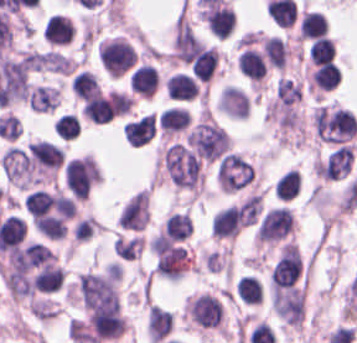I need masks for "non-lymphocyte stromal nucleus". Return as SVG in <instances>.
Instances as JSON below:
<instances>
[{"mask_svg": "<svg viewBox=\"0 0 357 343\" xmlns=\"http://www.w3.org/2000/svg\"><path fill=\"white\" fill-rule=\"evenodd\" d=\"M168 177L179 187L197 189L201 184L199 157L184 143L172 142L161 155Z\"/></svg>", "mask_w": 357, "mask_h": 343, "instance_id": "obj_1", "label": "non-lymphocyte stromal nucleus"}, {"mask_svg": "<svg viewBox=\"0 0 357 343\" xmlns=\"http://www.w3.org/2000/svg\"><path fill=\"white\" fill-rule=\"evenodd\" d=\"M313 129L318 139L343 145L357 133L354 114L339 107L320 106L312 115Z\"/></svg>", "mask_w": 357, "mask_h": 343, "instance_id": "obj_2", "label": "non-lymphocyte stromal nucleus"}, {"mask_svg": "<svg viewBox=\"0 0 357 343\" xmlns=\"http://www.w3.org/2000/svg\"><path fill=\"white\" fill-rule=\"evenodd\" d=\"M214 178L220 191L235 194L255 184L256 171L241 154L229 151L216 164Z\"/></svg>", "mask_w": 357, "mask_h": 343, "instance_id": "obj_3", "label": "non-lymphocyte stromal nucleus"}, {"mask_svg": "<svg viewBox=\"0 0 357 343\" xmlns=\"http://www.w3.org/2000/svg\"><path fill=\"white\" fill-rule=\"evenodd\" d=\"M186 142L199 158L210 162L230 149V137L225 128L210 120L199 122L187 135Z\"/></svg>", "mask_w": 357, "mask_h": 343, "instance_id": "obj_4", "label": "non-lymphocyte stromal nucleus"}, {"mask_svg": "<svg viewBox=\"0 0 357 343\" xmlns=\"http://www.w3.org/2000/svg\"><path fill=\"white\" fill-rule=\"evenodd\" d=\"M294 218L288 207H275L263 217L256 233V243H275L293 231Z\"/></svg>", "mask_w": 357, "mask_h": 343, "instance_id": "obj_5", "label": "non-lymphocyte stromal nucleus"}, {"mask_svg": "<svg viewBox=\"0 0 357 343\" xmlns=\"http://www.w3.org/2000/svg\"><path fill=\"white\" fill-rule=\"evenodd\" d=\"M156 128V116L151 112L131 121L124 127V137L131 146H142Z\"/></svg>", "mask_w": 357, "mask_h": 343, "instance_id": "obj_6", "label": "non-lymphocyte stromal nucleus"}, {"mask_svg": "<svg viewBox=\"0 0 357 343\" xmlns=\"http://www.w3.org/2000/svg\"><path fill=\"white\" fill-rule=\"evenodd\" d=\"M59 87L38 85L29 90L27 102L33 112H48L59 106Z\"/></svg>", "mask_w": 357, "mask_h": 343, "instance_id": "obj_7", "label": "non-lymphocyte stromal nucleus"}, {"mask_svg": "<svg viewBox=\"0 0 357 343\" xmlns=\"http://www.w3.org/2000/svg\"><path fill=\"white\" fill-rule=\"evenodd\" d=\"M147 330L150 340L160 343L173 330L172 314L152 306L148 312Z\"/></svg>", "mask_w": 357, "mask_h": 343, "instance_id": "obj_8", "label": "non-lymphocyte stromal nucleus"}, {"mask_svg": "<svg viewBox=\"0 0 357 343\" xmlns=\"http://www.w3.org/2000/svg\"><path fill=\"white\" fill-rule=\"evenodd\" d=\"M84 116L93 123H102L112 118L108 104L102 93L87 99L81 107Z\"/></svg>", "mask_w": 357, "mask_h": 343, "instance_id": "obj_9", "label": "non-lymphocyte stromal nucleus"}, {"mask_svg": "<svg viewBox=\"0 0 357 343\" xmlns=\"http://www.w3.org/2000/svg\"><path fill=\"white\" fill-rule=\"evenodd\" d=\"M143 238L137 236H116L114 253L122 260L134 261L141 255Z\"/></svg>", "mask_w": 357, "mask_h": 343, "instance_id": "obj_10", "label": "non-lymphocyte stromal nucleus"}, {"mask_svg": "<svg viewBox=\"0 0 357 343\" xmlns=\"http://www.w3.org/2000/svg\"><path fill=\"white\" fill-rule=\"evenodd\" d=\"M71 90L84 101L101 92L95 74L84 70L75 77Z\"/></svg>", "mask_w": 357, "mask_h": 343, "instance_id": "obj_11", "label": "non-lymphocyte stromal nucleus"}, {"mask_svg": "<svg viewBox=\"0 0 357 343\" xmlns=\"http://www.w3.org/2000/svg\"><path fill=\"white\" fill-rule=\"evenodd\" d=\"M275 94L277 101L288 107L299 101L302 91L296 81L280 76L276 81Z\"/></svg>", "mask_w": 357, "mask_h": 343, "instance_id": "obj_12", "label": "non-lymphocyte stromal nucleus"}, {"mask_svg": "<svg viewBox=\"0 0 357 343\" xmlns=\"http://www.w3.org/2000/svg\"><path fill=\"white\" fill-rule=\"evenodd\" d=\"M262 212V194H255L248 198L240 207V220L243 226H251L257 222Z\"/></svg>", "mask_w": 357, "mask_h": 343, "instance_id": "obj_13", "label": "non-lymphocyte stromal nucleus"}]
</instances>
